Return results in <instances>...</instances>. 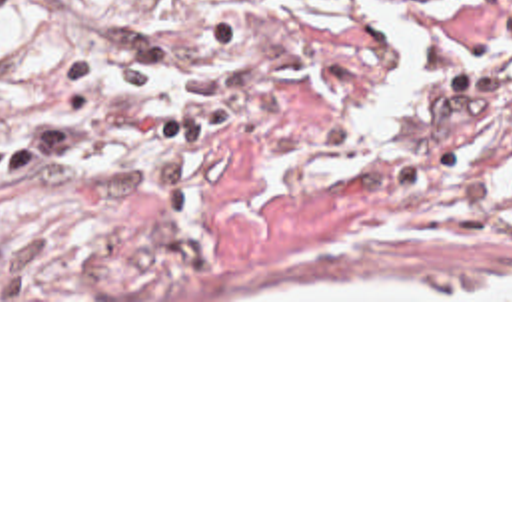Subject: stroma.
I'll list each match as a JSON object with an SVG mask.
<instances>
[{
	"label": "stroma",
	"instance_id": "stroma-1",
	"mask_svg": "<svg viewBox=\"0 0 512 512\" xmlns=\"http://www.w3.org/2000/svg\"><path fill=\"white\" fill-rule=\"evenodd\" d=\"M0 302H512V0H0Z\"/></svg>",
	"mask_w": 512,
	"mask_h": 512
}]
</instances>
